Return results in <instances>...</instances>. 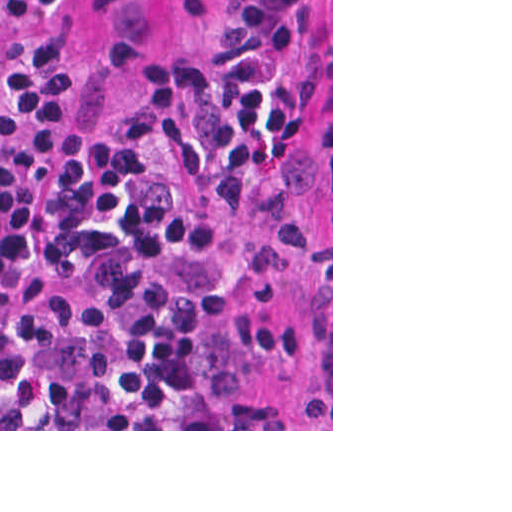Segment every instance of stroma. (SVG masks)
Wrapping results in <instances>:
<instances>
[{"mask_svg":"<svg viewBox=\"0 0 512 512\" xmlns=\"http://www.w3.org/2000/svg\"><path fill=\"white\" fill-rule=\"evenodd\" d=\"M34 28L83 54L87 123L139 105L173 50L207 45L219 0H56ZM223 356L267 387L298 429L0 431H333V0H302L284 56L271 154L253 218L216 284Z\"/></svg>","mask_w":512,"mask_h":512,"instance_id":"35a3bbf8","label":"stroma"}]
</instances>
